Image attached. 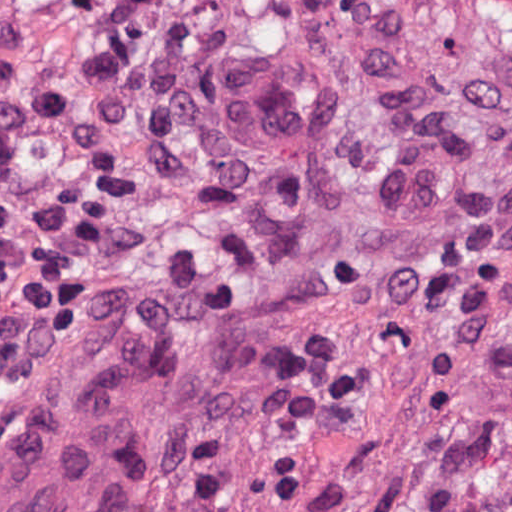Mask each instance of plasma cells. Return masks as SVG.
I'll use <instances>...</instances> for the list:
<instances>
[{
    "instance_id": "9512152a",
    "label": "plasma cells",
    "mask_w": 512,
    "mask_h": 512,
    "mask_svg": "<svg viewBox=\"0 0 512 512\" xmlns=\"http://www.w3.org/2000/svg\"><path fill=\"white\" fill-rule=\"evenodd\" d=\"M46 179L0 118V382H11L57 343L83 275L51 267L42 244Z\"/></svg>"
}]
</instances>
